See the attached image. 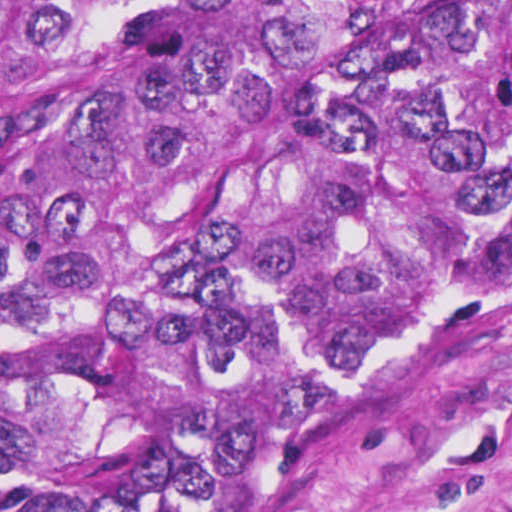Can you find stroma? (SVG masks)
<instances>
[{
    "label": "stroma",
    "mask_w": 512,
    "mask_h": 512,
    "mask_svg": "<svg viewBox=\"0 0 512 512\" xmlns=\"http://www.w3.org/2000/svg\"><path fill=\"white\" fill-rule=\"evenodd\" d=\"M295 512H512V287L431 323Z\"/></svg>",
    "instance_id": "1"
}]
</instances>
